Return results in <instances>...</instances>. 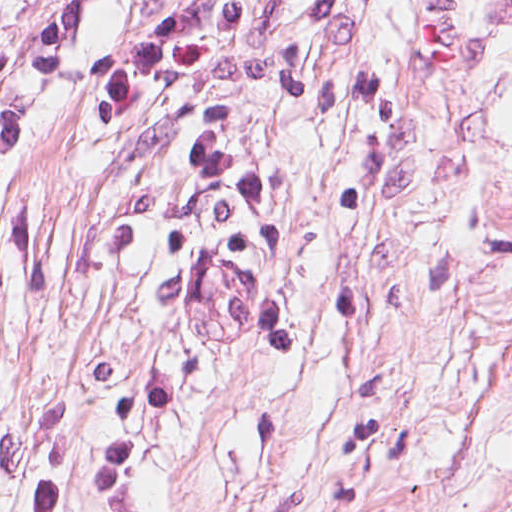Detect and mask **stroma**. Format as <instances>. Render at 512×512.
<instances>
[{"label": "stroma", "instance_id": "1", "mask_svg": "<svg viewBox=\"0 0 512 512\" xmlns=\"http://www.w3.org/2000/svg\"><path fill=\"white\" fill-rule=\"evenodd\" d=\"M0 512H512V0H0Z\"/></svg>", "mask_w": 512, "mask_h": 512}]
</instances>
